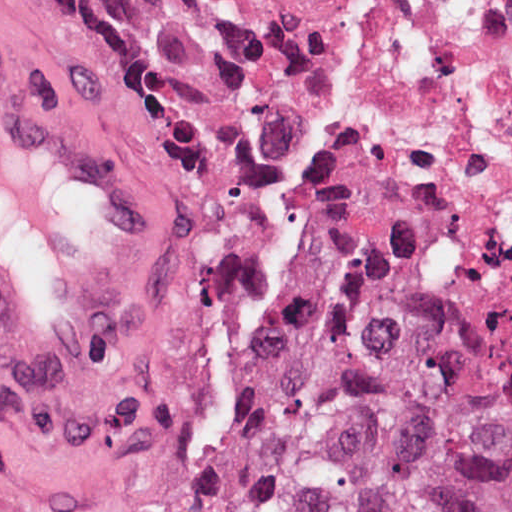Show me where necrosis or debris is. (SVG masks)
Wrapping results in <instances>:
<instances>
[{"label": "necrosis or debris", "instance_id": "1", "mask_svg": "<svg viewBox=\"0 0 512 512\" xmlns=\"http://www.w3.org/2000/svg\"><path fill=\"white\" fill-rule=\"evenodd\" d=\"M300 254L512 311V0H197Z\"/></svg>", "mask_w": 512, "mask_h": 512}]
</instances>
